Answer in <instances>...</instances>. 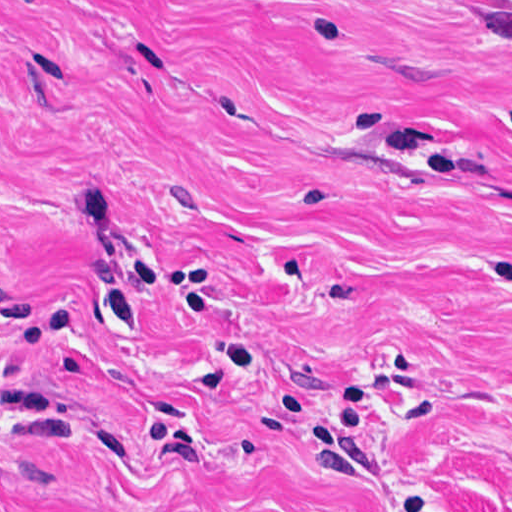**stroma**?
I'll use <instances>...</instances> for the list:
<instances>
[{
	"mask_svg": "<svg viewBox=\"0 0 512 512\" xmlns=\"http://www.w3.org/2000/svg\"><path fill=\"white\" fill-rule=\"evenodd\" d=\"M0 512H512V0H0Z\"/></svg>",
	"mask_w": 512,
	"mask_h": 512,
	"instance_id": "obj_1",
	"label": "stroma"
}]
</instances>
